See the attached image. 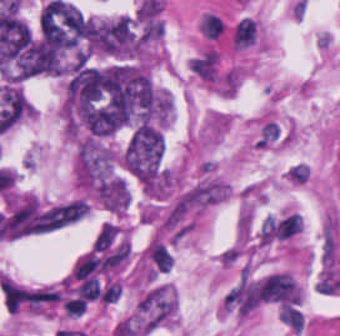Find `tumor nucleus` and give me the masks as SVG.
Returning a JSON list of instances; mask_svg holds the SVG:
<instances>
[{"instance_id":"2f306a5c","label":"tumor nucleus","mask_w":340,"mask_h":336,"mask_svg":"<svg viewBox=\"0 0 340 336\" xmlns=\"http://www.w3.org/2000/svg\"><path fill=\"white\" fill-rule=\"evenodd\" d=\"M74 171L77 188L86 198L128 199V178L119 153L105 141L79 139Z\"/></svg>"},{"instance_id":"8643909e","label":"tumor nucleus","mask_w":340,"mask_h":336,"mask_svg":"<svg viewBox=\"0 0 340 336\" xmlns=\"http://www.w3.org/2000/svg\"><path fill=\"white\" fill-rule=\"evenodd\" d=\"M163 152V132L147 124H139L126 144L121 162L137 179H153Z\"/></svg>"}]
</instances>
